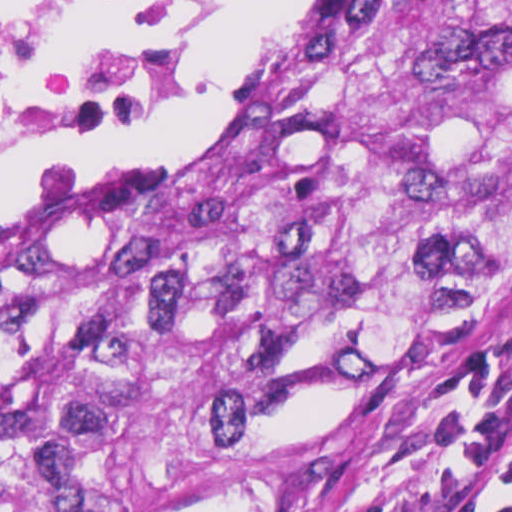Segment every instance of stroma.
Wrapping results in <instances>:
<instances>
[{
  "instance_id": "stroma-1",
  "label": "stroma",
  "mask_w": 512,
  "mask_h": 512,
  "mask_svg": "<svg viewBox=\"0 0 512 512\" xmlns=\"http://www.w3.org/2000/svg\"><path fill=\"white\" fill-rule=\"evenodd\" d=\"M372 1L297 0L238 87L188 136L151 158L75 162L0 192V220L137 176L218 129ZM205 6L208 28L211 0ZM33 158L1 165L0 178ZM201 512H512V269L415 324L345 421Z\"/></svg>"
}]
</instances>
